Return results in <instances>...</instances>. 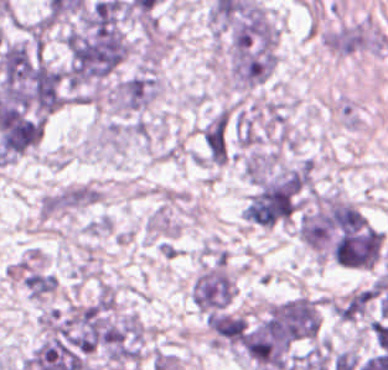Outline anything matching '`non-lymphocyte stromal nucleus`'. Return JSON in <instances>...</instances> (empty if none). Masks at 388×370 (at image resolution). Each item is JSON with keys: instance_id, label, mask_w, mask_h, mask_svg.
<instances>
[{"instance_id": "dd21d789", "label": "non-lymphocyte stromal nucleus", "mask_w": 388, "mask_h": 370, "mask_svg": "<svg viewBox=\"0 0 388 370\" xmlns=\"http://www.w3.org/2000/svg\"><path fill=\"white\" fill-rule=\"evenodd\" d=\"M229 113L217 111L202 127L201 141L206 160L224 164L228 153Z\"/></svg>"}]
</instances>
